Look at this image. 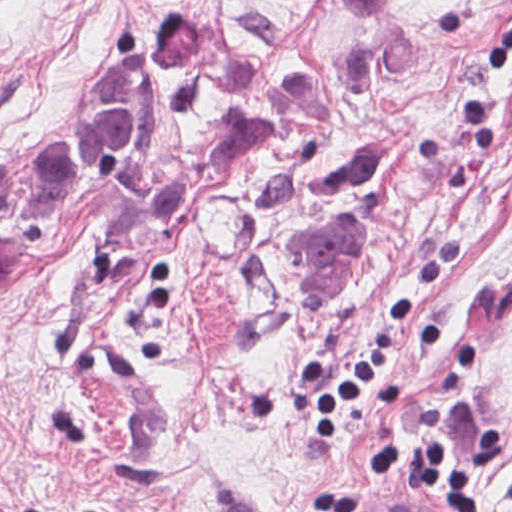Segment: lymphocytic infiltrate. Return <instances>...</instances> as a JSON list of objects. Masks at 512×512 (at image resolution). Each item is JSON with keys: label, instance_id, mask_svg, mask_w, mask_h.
Returning <instances> with one entry per match:
<instances>
[{"label": "lymphocytic infiltrate", "instance_id": "f902f5d3", "mask_svg": "<svg viewBox=\"0 0 512 512\" xmlns=\"http://www.w3.org/2000/svg\"><path fill=\"white\" fill-rule=\"evenodd\" d=\"M483 72L492 85H512V22L499 41L483 54ZM415 318V297L400 295L386 308L376 335L353 368L345 371L324 362L302 366L300 385L314 405L308 417L309 435L329 438L345 409L357 403L381 379ZM502 456L496 429L487 427L473 436L468 462L458 467L452 443L441 432L424 436L420 474L430 498L453 512H482L484 474ZM399 470V440L383 442L375 451L370 473L385 481ZM353 491H333L311 498L309 512H354Z\"/></svg>", "mask_w": 512, "mask_h": 512}]
</instances>
